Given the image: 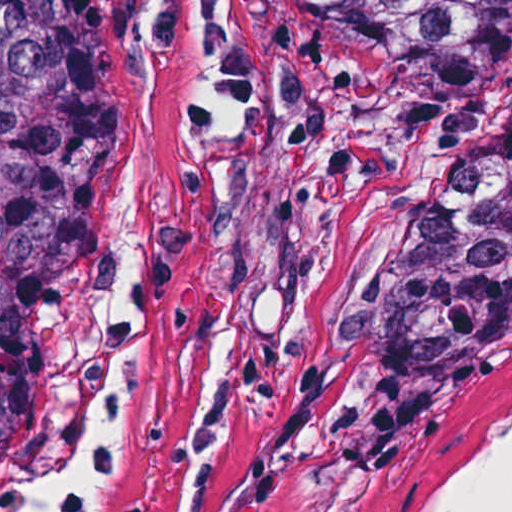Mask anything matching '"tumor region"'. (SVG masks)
<instances>
[{"mask_svg":"<svg viewBox=\"0 0 512 512\" xmlns=\"http://www.w3.org/2000/svg\"><path fill=\"white\" fill-rule=\"evenodd\" d=\"M343 23L411 82L506 84L512 0H273ZM79 0H0V492L45 372L65 272V77ZM512 319V113L430 203L370 358V469L390 480Z\"/></svg>","mask_w":512,"mask_h":512,"instance_id":"obj_1","label":"tumor region"}]
</instances>
